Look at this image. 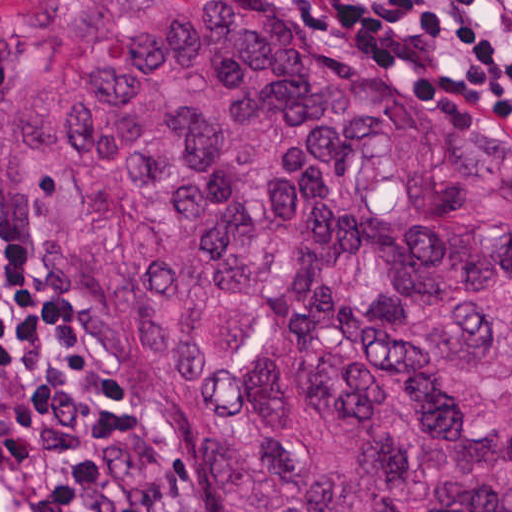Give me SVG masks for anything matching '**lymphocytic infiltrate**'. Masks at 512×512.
<instances>
[{"mask_svg":"<svg viewBox=\"0 0 512 512\" xmlns=\"http://www.w3.org/2000/svg\"><path fill=\"white\" fill-rule=\"evenodd\" d=\"M338 1L512 114V0ZM49 358L0 278V386ZM134 433L127 402L97 387L27 390L0 413V512H150L123 473Z\"/></svg>","mask_w":512,"mask_h":512,"instance_id":"1","label":"lymphocytic infiltrate"}]
</instances>
